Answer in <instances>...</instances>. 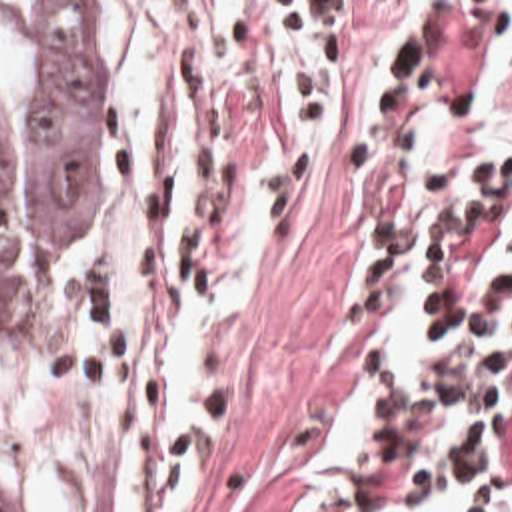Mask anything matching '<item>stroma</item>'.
<instances>
[{
  "label": "stroma",
  "mask_w": 512,
  "mask_h": 512,
  "mask_svg": "<svg viewBox=\"0 0 512 512\" xmlns=\"http://www.w3.org/2000/svg\"><path fill=\"white\" fill-rule=\"evenodd\" d=\"M148 8L184 66L174 178L194 206L200 283L246 228L260 283L216 363L196 512H290L294 467L346 385L372 375L368 256L420 198L444 138L512 76V0H0ZM126 178V100L114 214ZM92 228V232L98 228ZM53 281V317L70 264ZM380 399V389H378ZM0 507L21 512L0 489Z\"/></svg>",
  "instance_id": "35a3bbf8"
}]
</instances>
